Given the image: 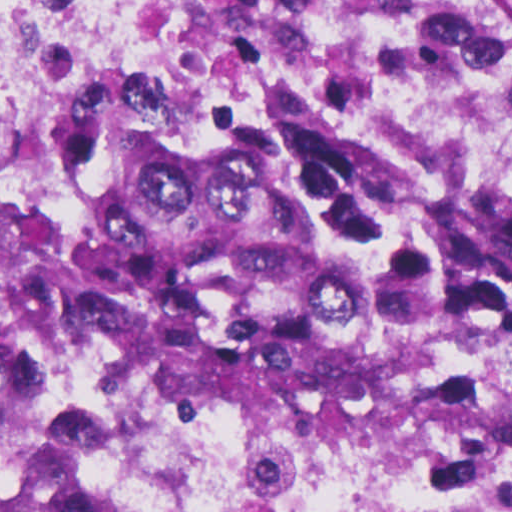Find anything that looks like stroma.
<instances>
[{
  "label": "stroma",
  "mask_w": 512,
  "mask_h": 512,
  "mask_svg": "<svg viewBox=\"0 0 512 512\" xmlns=\"http://www.w3.org/2000/svg\"><path fill=\"white\" fill-rule=\"evenodd\" d=\"M481 2L512 45V0H481Z\"/></svg>",
  "instance_id": "35a3bbf8"
}]
</instances>
